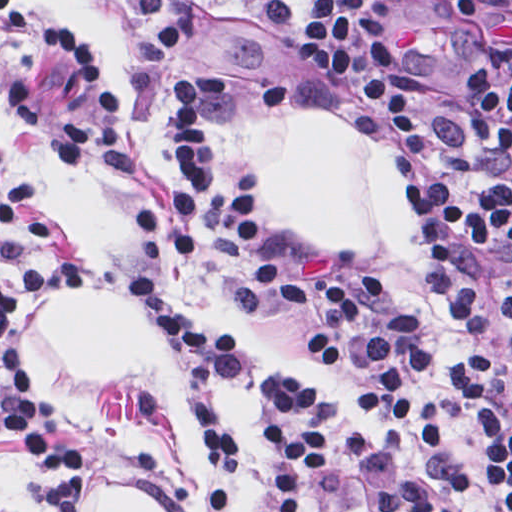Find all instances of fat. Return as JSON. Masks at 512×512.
Returning <instances> with one entry per match:
<instances>
[{
	"label": "fat",
	"mask_w": 512,
	"mask_h": 512,
	"mask_svg": "<svg viewBox=\"0 0 512 512\" xmlns=\"http://www.w3.org/2000/svg\"><path fill=\"white\" fill-rule=\"evenodd\" d=\"M91 26L124 107L139 125L141 55L121 21L84 0H56ZM240 137L255 158L259 186L279 223L309 249L363 255L387 279L392 298L414 309L444 354L459 333L444 316L416 229L391 186V150L339 121L305 113H249ZM44 350L72 372L142 385L163 400L174 441L194 479L201 512L197 432L175 376L141 309L119 289H86L44 301ZM82 512H161L129 489L91 491Z\"/></svg>",
	"instance_id": "1"
}]
</instances>
